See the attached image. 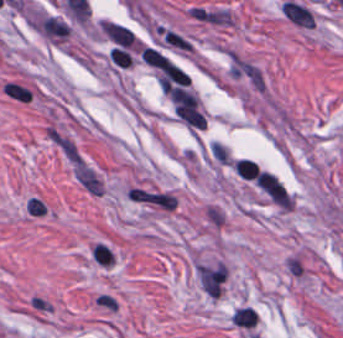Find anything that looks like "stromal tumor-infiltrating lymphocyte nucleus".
<instances>
[{
  "instance_id": "obj_1",
  "label": "stromal tumor-infiltrating lymphocyte nucleus",
  "mask_w": 343,
  "mask_h": 338,
  "mask_svg": "<svg viewBox=\"0 0 343 338\" xmlns=\"http://www.w3.org/2000/svg\"><path fill=\"white\" fill-rule=\"evenodd\" d=\"M34 89L19 80L7 79L0 93L7 99L18 105H29L33 97Z\"/></svg>"
},
{
  "instance_id": "obj_2",
  "label": "stromal tumor-infiltrating lymphocyte nucleus",
  "mask_w": 343,
  "mask_h": 338,
  "mask_svg": "<svg viewBox=\"0 0 343 338\" xmlns=\"http://www.w3.org/2000/svg\"><path fill=\"white\" fill-rule=\"evenodd\" d=\"M23 211L26 216L34 219H42L48 214L46 203L37 195H30L24 202Z\"/></svg>"
}]
</instances>
